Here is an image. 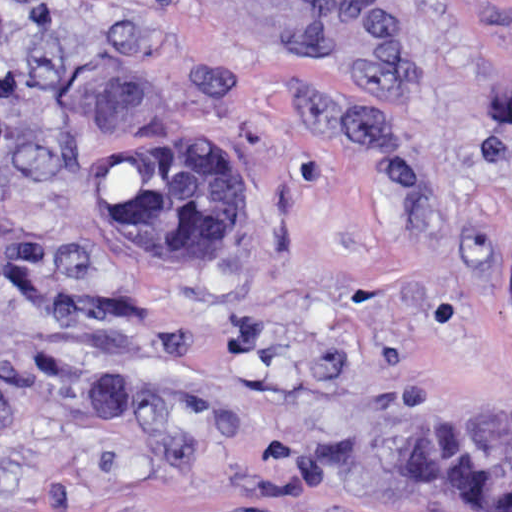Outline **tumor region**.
Returning a JSON list of instances; mask_svg holds the SVG:
<instances>
[{"instance_id": "tumor-region-1", "label": "tumor region", "mask_w": 512, "mask_h": 512, "mask_svg": "<svg viewBox=\"0 0 512 512\" xmlns=\"http://www.w3.org/2000/svg\"><path fill=\"white\" fill-rule=\"evenodd\" d=\"M107 224L166 273H223L249 245L247 171L199 122L111 152L95 181ZM413 496L465 512H512V453L481 446L449 417L417 425L397 461Z\"/></svg>"}]
</instances>
